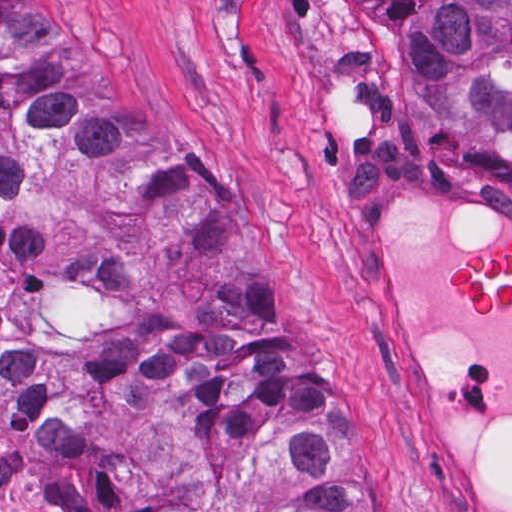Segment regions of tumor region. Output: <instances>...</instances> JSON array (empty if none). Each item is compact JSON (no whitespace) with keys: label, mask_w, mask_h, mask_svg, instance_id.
<instances>
[{"label":"tumor region","mask_w":512,"mask_h":512,"mask_svg":"<svg viewBox=\"0 0 512 512\" xmlns=\"http://www.w3.org/2000/svg\"><path fill=\"white\" fill-rule=\"evenodd\" d=\"M370 1L435 122L512 127V0ZM0 412L42 512H404L213 182L28 0H0Z\"/></svg>","instance_id":"1"}]
</instances>
